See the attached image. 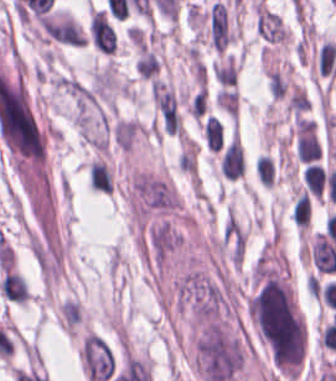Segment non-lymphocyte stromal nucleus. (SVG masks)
I'll list each match as a JSON object with an SVG mask.
<instances>
[{"label": "non-lymphocyte stromal nucleus", "mask_w": 336, "mask_h": 381, "mask_svg": "<svg viewBox=\"0 0 336 381\" xmlns=\"http://www.w3.org/2000/svg\"><path fill=\"white\" fill-rule=\"evenodd\" d=\"M208 36L213 50L223 51L235 37L229 13L222 3H212L207 15Z\"/></svg>", "instance_id": "obj_1"}]
</instances>
